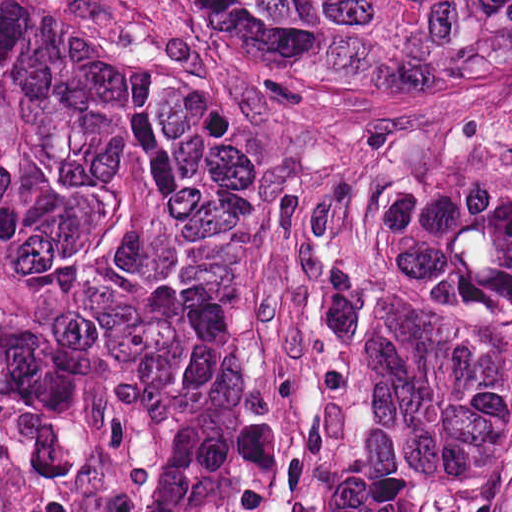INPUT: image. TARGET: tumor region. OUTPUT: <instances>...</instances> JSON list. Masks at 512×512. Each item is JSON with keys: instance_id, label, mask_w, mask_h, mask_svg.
Returning a JSON list of instances; mask_svg holds the SVG:
<instances>
[{"instance_id": "e687c5a6", "label": "tumor region", "mask_w": 512, "mask_h": 512, "mask_svg": "<svg viewBox=\"0 0 512 512\" xmlns=\"http://www.w3.org/2000/svg\"><path fill=\"white\" fill-rule=\"evenodd\" d=\"M333 69H433L512 89V0H189ZM118 181V61L52 0H0V253L82 284ZM285 512H512V135L415 158L371 324Z\"/></svg>"}]
</instances>
